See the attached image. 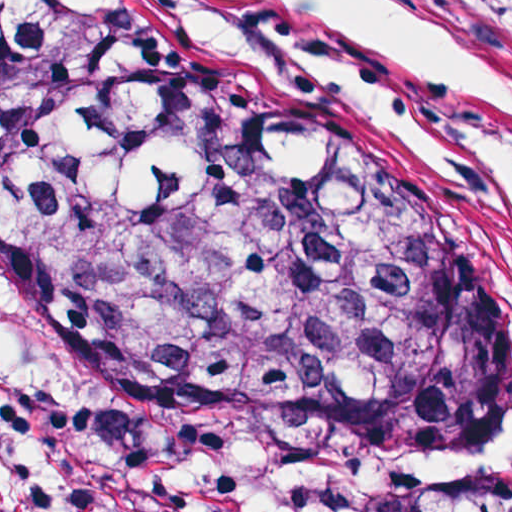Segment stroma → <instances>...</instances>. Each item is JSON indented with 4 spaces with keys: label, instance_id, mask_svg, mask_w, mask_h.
<instances>
[{
    "label": "stroma",
    "instance_id": "35a3bbf8",
    "mask_svg": "<svg viewBox=\"0 0 512 512\" xmlns=\"http://www.w3.org/2000/svg\"><path fill=\"white\" fill-rule=\"evenodd\" d=\"M99 1L139 14L121 0ZM448 1L512 49V0ZM242 70L308 92L275 74ZM0 337L25 373L62 401L91 466V487L100 512H127L119 481V453L126 430L192 432L205 451L344 447L400 451L512 470V428L487 459L480 456L468 438L365 444L311 431L266 426L239 414L201 408L175 396L137 391L105 371L37 350L1 309Z\"/></svg>",
    "mask_w": 512,
    "mask_h": 512
}]
</instances>
